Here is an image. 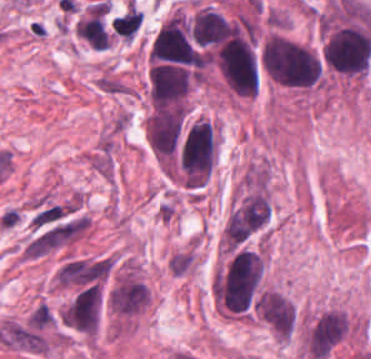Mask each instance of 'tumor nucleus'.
Wrapping results in <instances>:
<instances>
[{
  "instance_id": "1",
  "label": "tumor nucleus",
  "mask_w": 371,
  "mask_h": 359,
  "mask_svg": "<svg viewBox=\"0 0 371 359\" xmlns=\"http://www.w3.org/2000/svg\"><path fill=\"white\" fill-rule=\"evenodd\" d=\"M109 311L121 317H130L147 306L144 284L132 271H125L113 283L107 298Z\"/></svg>"
},
{
  "instance_id": "2",
  "label": "tumor nucleus",
  "mask_w": 371,
  "mask_h": 359,
  "mask_svg": "<svg viewBox=\"0 0 371 359\" xmlns=\"http://www.w3.org/2000/svg\"><path fill=\"white\" fill-rule=\"evenodd\" d=\"M192 252L179 251L168 260V267L174 275H183L192 265Z\"/></svg>"
}]
</instances>
